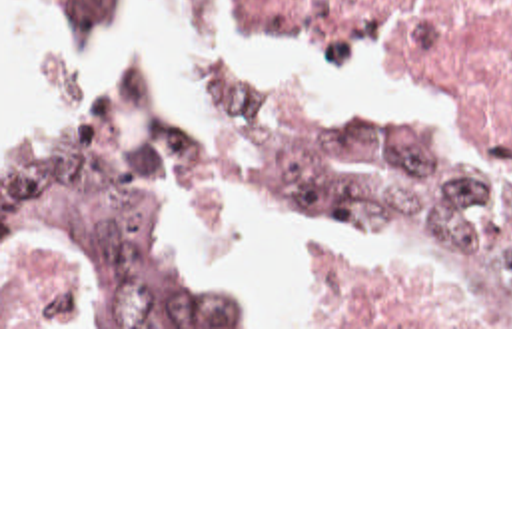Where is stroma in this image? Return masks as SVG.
<instances>
[{
	"instance_id": "1",
	"label": "stroma",
	"mask_w": 512,
	"mask_h": 512,
	"mask_svg": "<svg viewBox=\"0 0 512 512\" xmlns=\"http://www.w3.org/2000/svg\"><path fill=\"white\" fill-rule=\"evenodd\" d=\"M162 10L182 26L202 32L178 18H190L182 0H162ZM44 22L86 40H116L136 30L144 0H134V14L120 26H70L44 12ZM238 16L222 0L218 18ZM371 32L369 36H373ZM395 44V42H393ZM108 79H148L126 67ZM0 85H2V16H0ZM218 223H260L288 229L310 239L319 267V301L325 325H262L252 293V325H116L92 307L82 293L80 277L60 245H20L2 253V157H0V329H512V325L479 323L461 299L457 283L429 263L383 259L349 241L304 233L282 219L214 217L182 223L184 245L202 257L248 277L226 257L208 249L204 235ZM252 289V287H250Z\"/></svg>"
}]
</instances>
